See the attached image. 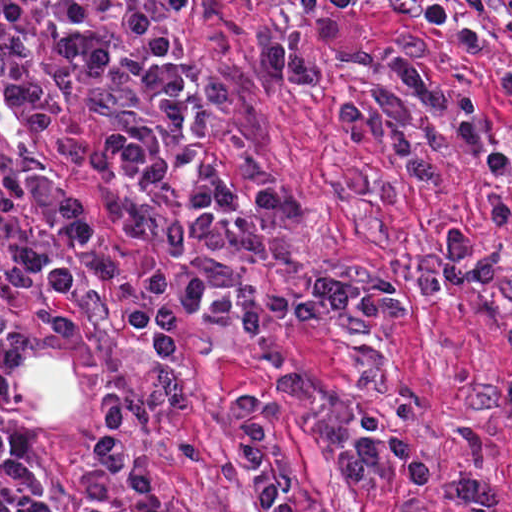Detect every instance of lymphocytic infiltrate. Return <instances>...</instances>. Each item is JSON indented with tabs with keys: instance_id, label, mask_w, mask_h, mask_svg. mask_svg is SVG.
Masks as SVG:
<instances>
[{
	"instance_id": "f902f5d3",
	"label": "lymphocytic infiltrate",
	"mask_w": 512,
	"mask_h": 512,
	"mask_svg": "<svg viewBox=\"0 0 512 512\" xmlns=\"http://www.w3.org/2000/svg\"><path fill=\"white\" fill-rule=\"evenodd\" d=\"M239 461L249 486L271 512H297V470L284 459L265 405L256 398L237 402ZM127 402L111 392L98 427L81 445L86 463L76 478L81 494L99 501L91 512H189L161 497L146 461L127 451ZM345 478L357 485L382 470H395L411 493L436 487V468L402 428H377L357 439L341 463Z\"/></svg>"
}]
</instances>
